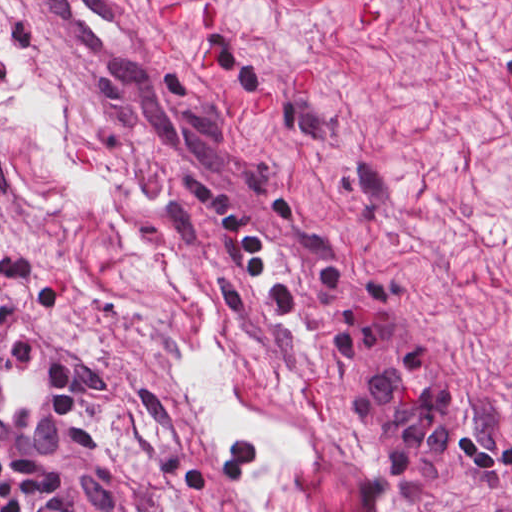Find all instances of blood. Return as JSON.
Returning <instances> with one entry per match:
<instances>
[{
    "label": "blood",
    "mask_w": 512,
    "mask_h": 512,
    "mask_svg": "<svg viewBox=\"0 0 512 512\" xmlns=\"http://www.w3.org/2000/svg\"><path fill=\"white\" fill-rule=\"evenodd\" d=\"M206 29L211 30L218 23L221 22V16L218 11L211 10L202 5ZM162 20H180V3L173 5L168 10L162 13L155 14ZM385 17L381 15L377 5L367 4L361 8L355 18V29L359 32H372L383 21ZM214 58V50L207 47L202 63V73L205 74L209 64ZM309 76V90L313 79V69L306 70L299 78L292 82V95L296 97H303L307 79Z\"/></svg>",
    "instance_id": "blood-1"
}]
</instances>
